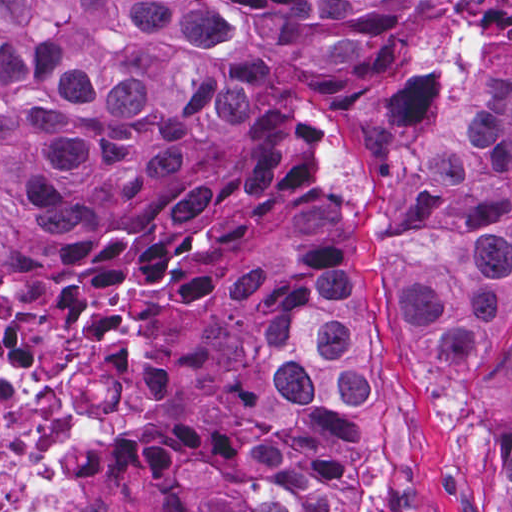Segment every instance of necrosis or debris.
<instances>
[{"mask_svg":"<svg viewBox=\"0 0 512 512\" xmlns=\"http://www.w3.org/2000/svg\"><path fill=\"white\" fill-rule=\"evenodd\" d=\"M20 312L21 303L0 297V512L8 484L83 420L152 417L179 403L166 408L179 391L177 350L142 337L129 308L111 302L72 328L35 327ZM144 420L114 440L77 443L80 512L95 510Z\"/></svg>","mask_w":512,"mask_h":512,"instance_id":"necrosis-or-debris-1","label":"necrosis or debris"}]
</instances>
